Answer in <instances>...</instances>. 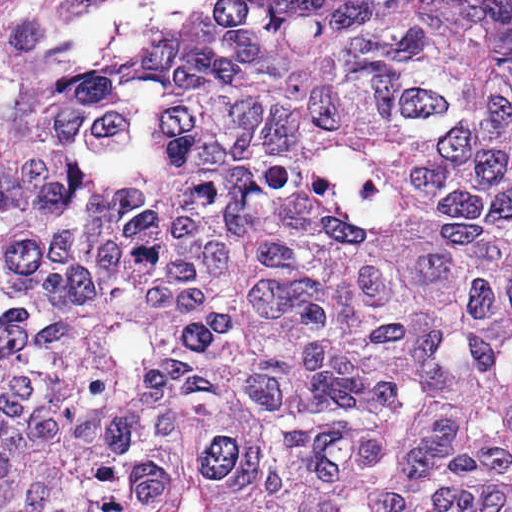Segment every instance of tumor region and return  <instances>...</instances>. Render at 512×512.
<instances>
[{
	"label": "tumor region",
	"mask_w": 512,
	"mask_h": 512,
	"mask_svg": "<svg viewBox=\"0 0 512 512\" xmlns=\"http://www.w3.org/2000/svg\"><path fill=\"white\" fill-rule=\"evenodd\" d=\"M14 2L0 512H512V0Z\"/></svg>",
	"instance_id": "obj_1"
}]
</instances>
